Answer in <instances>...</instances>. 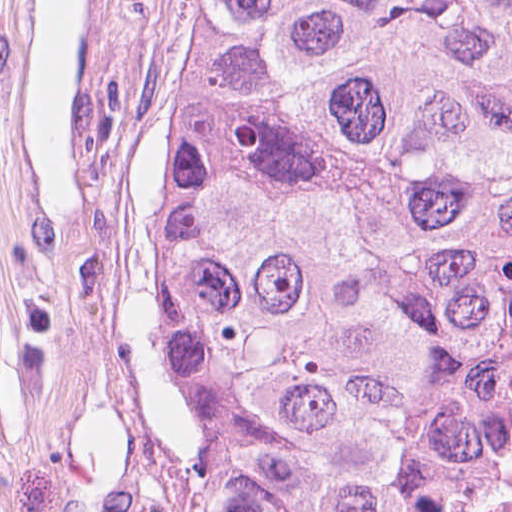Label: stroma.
<instances>
[{"instance_id":"35a3bbf8","label":"stroma","mask_w":512,"mask_h":512,"mask_svg":"<svg viewBox=\"0 0 512 512\" xmlns=\"http://www.w3.org/2000/svg\"><path fill=\"white\" fill-rule=\"evenodd\" d=\"M134 2L79 1L64 67V228L32 239L25 0H0V512L137 510L139 444L95 323L111 70Z\"/></svg>"}]
</instances>
